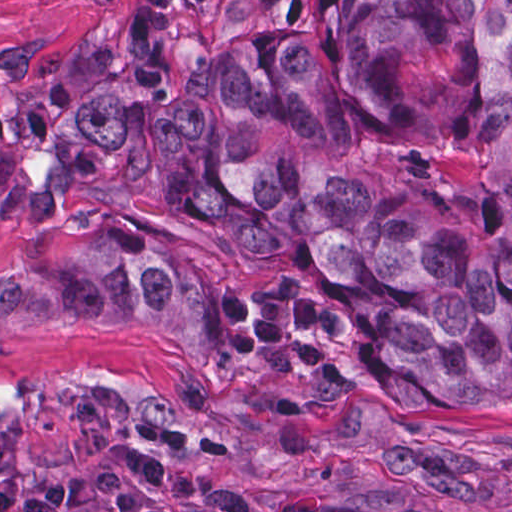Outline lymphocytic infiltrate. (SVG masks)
<instances>
[{
  "label": "lymphocytic infiltrate",
  "mask_w": 512,
  "mask_h": 512,
  "mask_svg": "<svg viewBox=\"0 0 512 512\" xmlns=\"http://www.w3.org/2000/svg\"><path fill=\"white\" fill-rule=\"evenodd\" d=\"M168 460L163 446L126 440L68 494H33L17 512H206L163 489Z\"/></svg>",
  "instance_id": "1"
}]
</instances>
